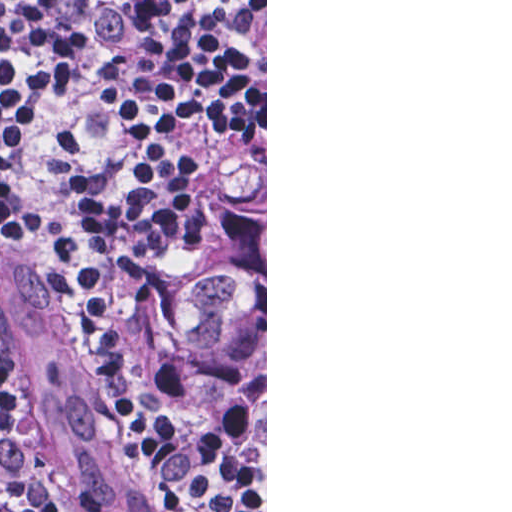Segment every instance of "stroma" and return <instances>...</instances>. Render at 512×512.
<instances>
[{
  "label": "stroma",
  "mask_w": 512,
  "mask_h": 512,
  "mask_svg": "<svg viewBox=\"0 0 512 512\" xmlns=\"http://www.w3.org/2000/svg\"><path fill=\"white\" fill-rule=\"evenodd\" d=\"M255 158H265V506L252 501L229 479L207 464L187 442L175 433L152 407L138 383L137 387L139 396L151 417L170 444L186 459L196 472L202 475L222 494L245 509L251 512H267V0H265V148L249 152H190L178 172V252L136 306L121 317H111L119 331L120 326L128 318L149 309L164 300L170 293L183 275L194 252L198 242L199 221L205 206L216 196L221 184L237 164ZM7 238L21 240L22 242L20 243L43 254L52 267H54L67 302L99 369L103 388L121 432L129 445L131 458L139 465L144 477L160 501L171 512H174L141 466L136 451L119 421V405L113 390L108 360L82 311L80 301L65 280L54 254L42 238L14 219L0 213V243ZM0 385L12 419L16 452L30 478L31 512H48L47 494L41 472L33 458L29 440L25 433L18 392L1 366Z\"/></svg>",
  "instance_id": "stroma-1"
}]
</instances>
